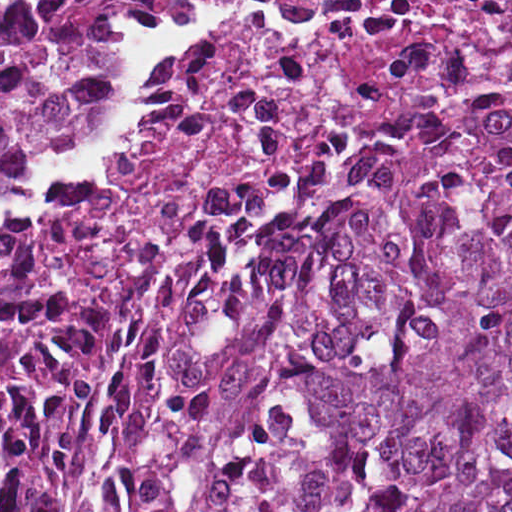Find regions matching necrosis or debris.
<instances>
[{"label":"necrosis or debris","instance_id":"4bbe7bcc","mask_svg":"<svg viewBox=\"0 0 512 512\" xmlns=\"http://www.w3.org/2000/svg\"><path fill=\"white\" fill-rule=\"evenodd\" d=\"M102 155L45 197L59 287L113 301L135 266L228 225L283 166L445 81L512 72V0H188L135 35Z\"/></svg>","mask_w":512,"mask_h":512}]
</instances>
